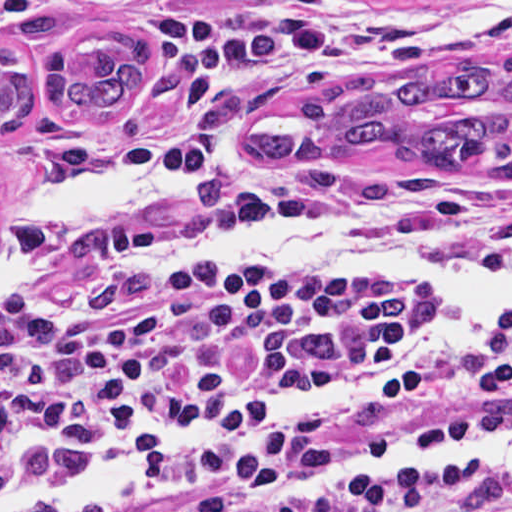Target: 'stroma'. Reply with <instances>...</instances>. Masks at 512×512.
Masks as SVG:
<instances>
[{
	"instance_id": "35a3bbf8",
	"label": "stroma",
	"mask_w": 512,
	"mask_h": 512,
	"mask_svg": "<svg viewBox=\"0 0 512 512\" xmlns=\"http://www.w3.org/2000/svg\"><path fill=\"white\" fill-rule=\"evenodd\" d=\"M92 33L139 39L144 73L139 89L109 118L75 119L50 104L48 63L57 50L70 56ZM0 45L16 48L34 76L26 122L0 132V225L28 192L80 164L137 159L179 175L172 185L119 200L87 231L0 275V289L84 252L163 258L156 249L168 244L225 237L325 208L407 204L424 237L464 251L498 253L512 237V184L372 156L263 170L238 155L243 132L267 108L331 78L473 56L512 62V0H0ZM190 273L224 286L344 287ZM388 365L297 381L357 379ZM450 399L441 369L404 371L400 385L352 399L293 430L426 436L440 425ZM172 433L194 432L180 425L140 434L127 445ZM241 444L196 449L158 474L206 468ZM82 459L30 448L0 392L4 492Z\"/></svg>"
}]
</instances>
